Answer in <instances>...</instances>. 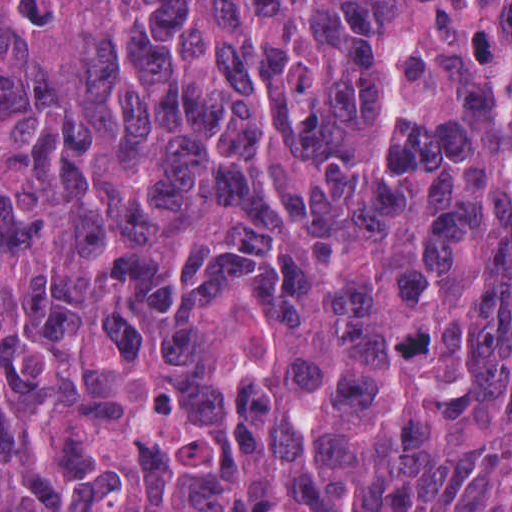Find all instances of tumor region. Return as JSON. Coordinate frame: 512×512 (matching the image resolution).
<instances>
[{"mask_svg":"<svg viewBox=\"0 0 512 512\" xmlns=\"http://www.w3.org/2000/svg\"><path fill=\"white\" fill-rule=\"evenodd\" d=\"M0 512H512V0H0Z\"/></svg>","mask_w":512,"mask_h":512,"instance_id":"e687c5a6","label":"tumor region"}]
</instances>
